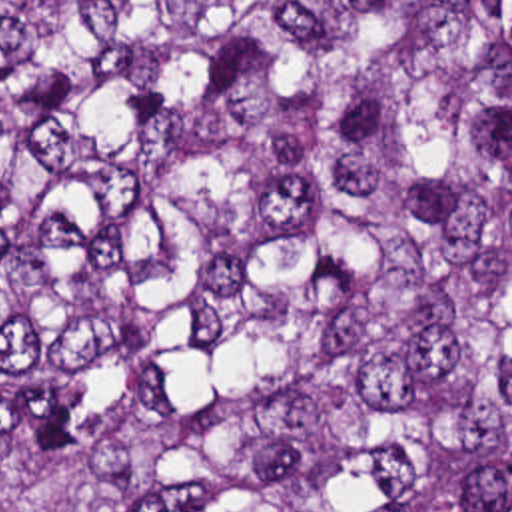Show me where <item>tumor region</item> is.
<instances>
[{
	"label": "tumor region",
	"mask_w": 512,
	"mask_h": 512,
	"mask_svg": "<svg viewBox=\"0 0 512 512\" xmlns=\"http://www.w3.org/2000/svg\"><path fill=\"white\" fill-rule=\"evenodd\" d=\"M0 512H512V0H0Z\"/></svg>",
	"instance_id": "1"
}]
</instances>
